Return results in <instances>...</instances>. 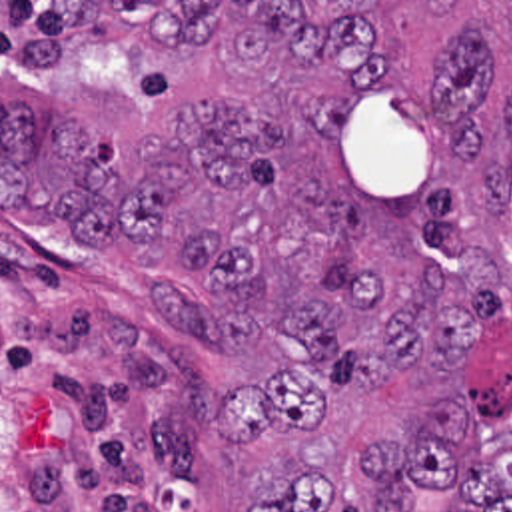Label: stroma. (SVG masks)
Wrapping results in <instances>:
<instances>
[{
    "label": "stroma",
    "mask_w": 512,
    "mask_h": 512,
    "mask_svg": "<svg viewBox=\"0 0 512 512\" xmlns=\"http://www.w3.org/2000/svg\"><path fill=\"white\" fill-rule=\"evenodd\" d=\"M90 2V40L34 80H0L36 128L74 118L100 136L112 172H134L138 140L166 136L174 106L235 88L229 46L178 50L122 26L116 2H512V0H0ZM158 283L206 297L178 264L140 270L132 244L78 242L58 218L0 208V512H243L249 493L297 477L287 427L225 445L218 395L295 367L279 339L212 355L168 327Z\"/></svg>",
    "instance_id": "35a3bbf8"
}]
</instances>
